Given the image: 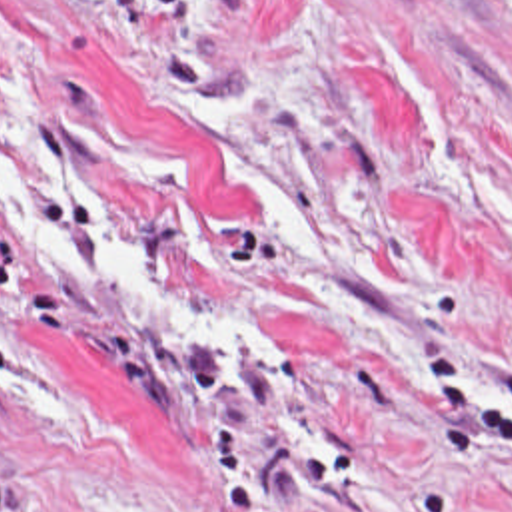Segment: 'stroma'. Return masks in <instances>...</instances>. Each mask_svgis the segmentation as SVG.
Wrapping results in <instances>:
<instances>
[{
    "label": "stroma",
    "mask_w": 512,
    "mask_h": 512,
    "mask_svg": "<svg viewBox=\"0 0 512 512\" xmlns=\"http://www.w3.org/2000/svg\"><path fill=\"white\" fill-rule=\"evenodd\" d=\"M36 114L276 351L172 339L0 226V512H512V0H0L18 156Z\"/></svg>",
    "instance_id": "1"
}]
</instances>
